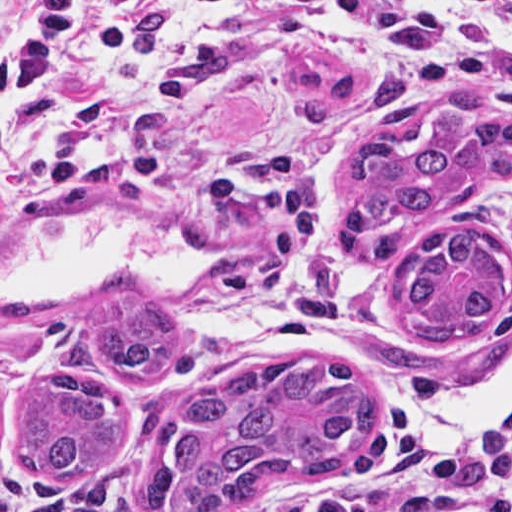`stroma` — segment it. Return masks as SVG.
Instances as JSON below:
<instances>
[{
  "label": "stroma",
  "instance_id": "35a3bbf8",
  "mask_svg": "<svg viewBox=\"0 0 512 512\" xmlns=\"http://www.w3.org/2000/svg\"><path fill=\"white\" fill-rule=\"evenodd\" d=\"M24 1L0 0V29ZM411 1L512 55V27L485 11L460 0ZM197 38L220 40L227 66L192 109L148 114L147 143L170 159L218 153L251 165L276 155L313 162L329 202L319 249L301 255L254 215L125 182L84 180L52 204L1 209L0 229L48 211H142L205 266L222 271L190 287L146 291L170 324L169 356L149 379L75 367L61 356L68 335L99 317L113 291L72 302H0V512L94 509L124 491L137 495L153 459L170 448L181 405L200 383L233 367L317 353L361 379L371 432L345 469L319 483L275 484L247 509L288 512L306 496L345 483L377 428L400 406L423 401L451 415L481 408L459 404L474 382L512 355V161L477 187L382 229L348 231L336 217L342 166L359 140L388 135L409 153L421 151L477 120L512 114V102L464 94L440 74H391L351 44L312 40L252 7L191 24L149 57L150 79L168 83L175 47ZM133 76L100 33L90 52L88 92L59 99L0 88V165L40 164ZM448 227L468 228L495 244L505 261V306L471 339L425 343L403 323L396 286L427 238ZM53 372L103 378L131 418V440L117 461L75 485L42 482L11 455L26 391Z\"/></svg>",
  "mask_w": 512,
  "mask_h": 512
}]
</instances>
